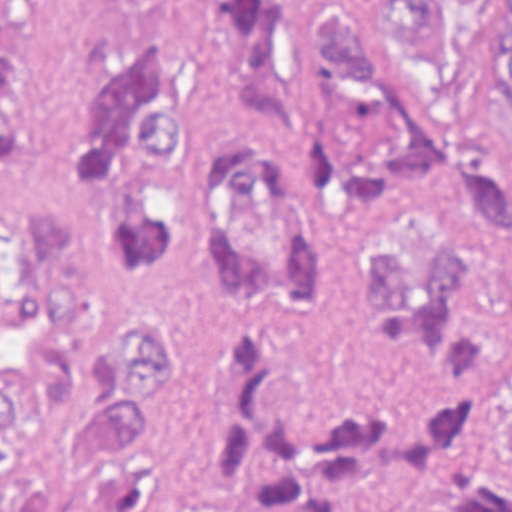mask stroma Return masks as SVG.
Returning <instances> with one entry per match:
<instances>
[{
  "label": "stroma",
  "instance_id": "1",
  "mask_svg": "<svg viewBox=\"0 0 512 512\" xmlns=\"http://www.w3.org/2000/svg\"><path fill=\"white\" fill-rule=\"evenodd\" d=\"M23 16V120L0 150V215L34 204L64 167L81 125V99L102 59L167 46L188 0H7ZM319 8L360 24L380 45L397 81L412 88L382 31L375 0H279L276 98L268 138L301 192L309 237L328 276L337 318L290 327L251 316L211 282L191 291V331L203 350V391L163 453L187 460L210 420L239 338L276 350L284 390L401 403L417 387V362L385 331L373 290L356 274V249L373 233L472 188L512 191L494 173L426 178L407 186L384 218L334 210L294 135L303 67Z\"/></svg>",
  "mask_w": 512,
  "mask_h": 512
}]
</instances>
